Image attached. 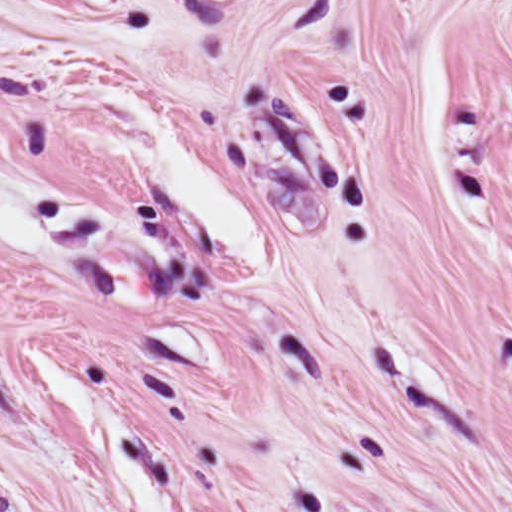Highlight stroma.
<instances>
[{"label": "stroma", "instance_id": "stroma-1", "mask_svg": "<svg viewBox=\"0 0 512 512\" xmlns=\"http://www.w3.org/2000/svg\"><path fill=\"white\" fill-rule=\"evenodd\" d=\"M0 512H512V0L0 172Z\"/></svg>", "mask_w": 512, "mask_h": 512}]
</instances>
